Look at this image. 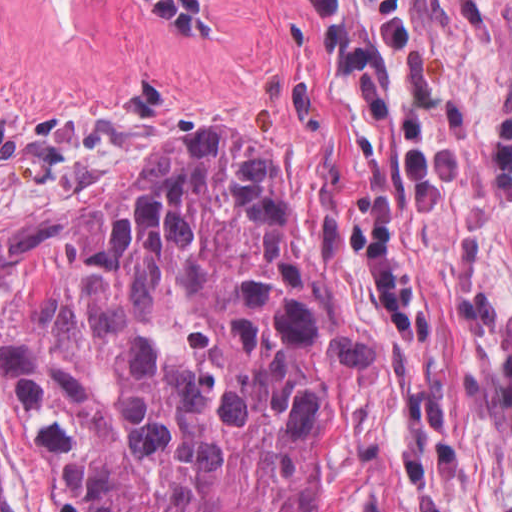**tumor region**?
<instances>
[{
    "label": "tumor region",
    "mask_w": 512,
    "mask_h": 512,
    "mask_svg": "<svg viewBox=\"0 0 512 512\" xmlns=\"http://www.w3.org/2000/svg\"><path fill=\"white\" fill-rule=\"evenodd\" d=\"M373 477L388 469L392 366L364 342L278 158L233 135L179 140Z\"/></svg>",
    "instance_id": "tumor-region-1"
}]
</instances>
